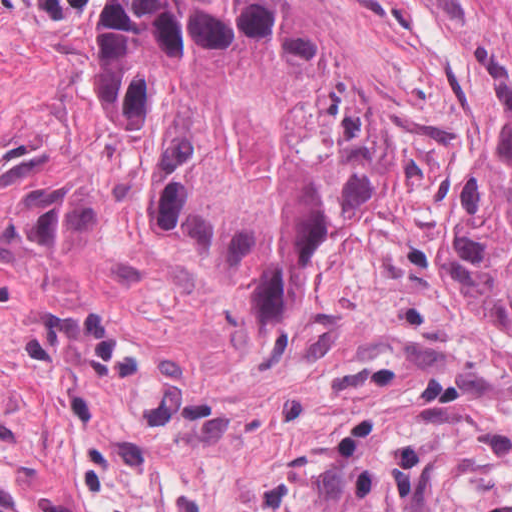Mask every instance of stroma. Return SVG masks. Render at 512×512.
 I'll list each match as a JSON object with an SVG mask.
<instances>
[{
	"instance_id": "1",
	"label": "stroma",
	"mask_w": 512,
	"mask_h": 512,
	"mask_svg": "<svg viewBox=\"0 0 512 512\" xmlns=\"http://www.w3.org/2000/svg\"><path fill=\"white\" fill-rule=\"evenodd\" d=\"M65 0H0V512H361Z\"/></svg>"
}]
</instances>
